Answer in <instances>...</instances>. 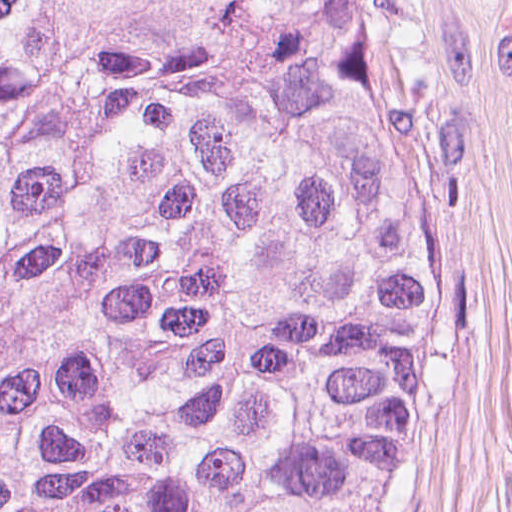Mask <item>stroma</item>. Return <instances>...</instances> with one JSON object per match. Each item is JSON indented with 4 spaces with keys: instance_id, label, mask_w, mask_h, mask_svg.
I'll list each match as a JSON object with an SVG mask.
<instances>
[{
    "instance_id": "35a3bbf8",
    "label": "stroma",
    "mask_w": 512,
    "mask_h": 512,
    "mask_svg": "<svg viewBox=\"0 0 512 512\" xmlns=\"http://www.w3.org/2000/svg\"><path fill=\"white\" fill-rule=\"evenodd\" d=\"M407 5L457 267L372 512H512V0Z\"/></svg>"
}]
</instances>
